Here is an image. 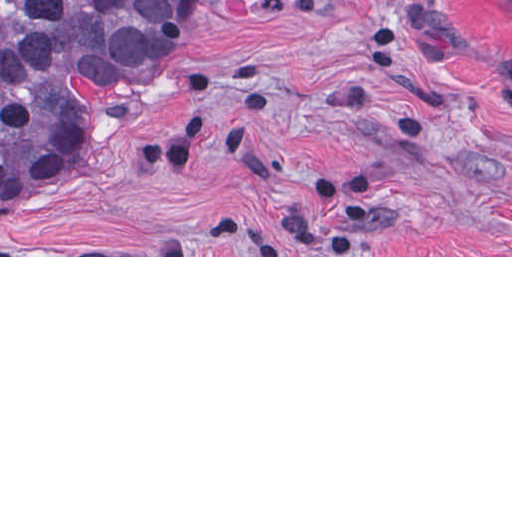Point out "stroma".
Here are the masks:
<instances>
[{"label": "stroma", "mask_w": 512, "mask_h": 512, "mask_svg": "<svg viewBox=\"0 0 512 512\" xmlns=\"http://www.w3.org/2000/svg\"><path fill=\"white\" fill-rule=\"evenodd\" d=\"M0 257H512V4L210 0Z\"/></svg>", "instance_id": "stroma-1"}]
</instances>
